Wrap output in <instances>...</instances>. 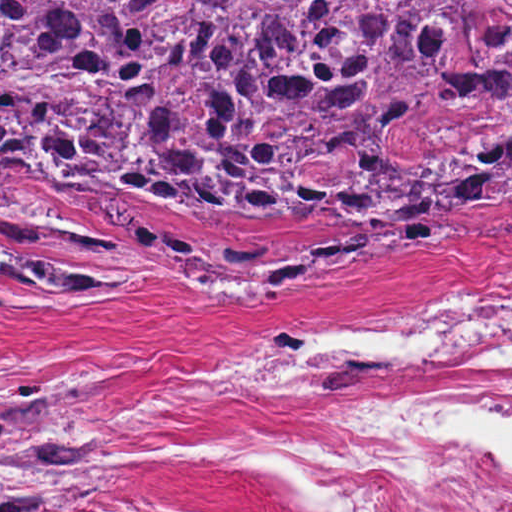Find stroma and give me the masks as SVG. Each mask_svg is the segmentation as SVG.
Segmentation results:
<instances>
[{
	"label": "stroma",
	"mask_w": 512,
	"mask_h": 512,
	"mask_svg": "<svg viewBox=\"0 0 512 512\" xmlns=\"http://www.w3.org/2000/svg\"><path fill=\"white\" fill-rule=\"evenodd\" d=\"M0 199V378L52 380L96 416L119 488L73 512H334L306 473L313 437L382 401L496 398L446 422L512 464V362L207 383L277 325L425 273H512V198L392 218L321 192L253 225L176 192L135 196L25 172Z\"/></svg>",
	"instance_id": "1"
}]
</instances>
